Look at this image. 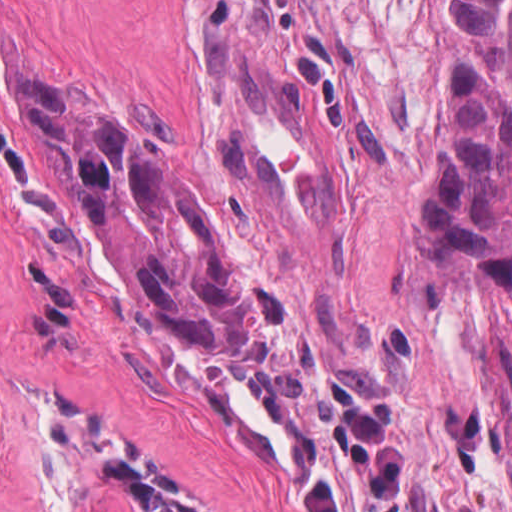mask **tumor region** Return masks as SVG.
Returning <instances> with one entry per match:
<instances>
[{"instance_id":"e687c5a6","label":"tumor region","mask_w":512,"mask_h":512,"mask_svg":"<svg viewBox=\"0 0 512 512\" xmlns=\"http://www.w3.org/2000/svg\"><path fill=\"white\" fill-rule=\"evenodd\" d=\"M424 185L432 241L512 288V0H455ZM76 192L104 274L130 309L205 359H255L241 261L187 167L85 98L20 76Z\"/></svg>"}]
</instances>
